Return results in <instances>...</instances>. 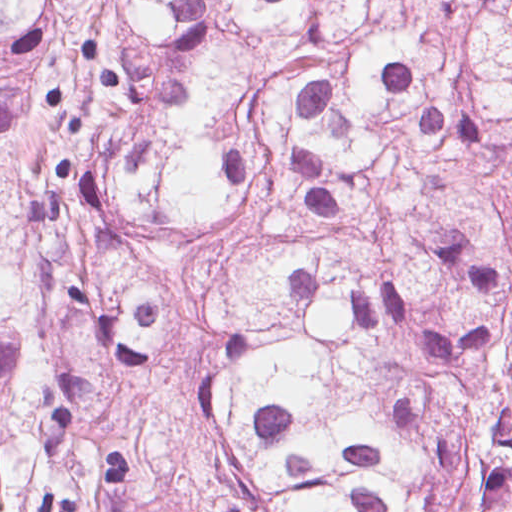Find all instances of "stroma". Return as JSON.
Instances as JSON below:
<instances>
[{"mask_svg": "<svg viewBox=\"0 0 512 512\" xmlns=\"http://www.w3.org/2000/svg\"><path fill=\"white\" fill-rule=\"evenodd\" d=\"M86 275L111 278L118 281H149L136 275L106 266L86 258Z\"/></svg>", "mask_w": 512, "mask_h": 512, "instance_id": "1", "label": "stroma"}]
</instances>
